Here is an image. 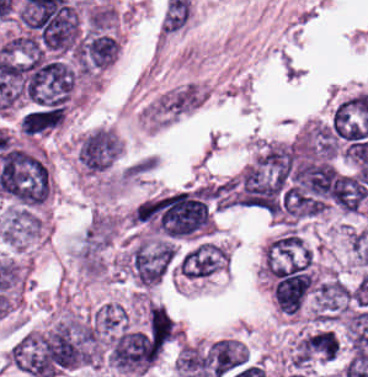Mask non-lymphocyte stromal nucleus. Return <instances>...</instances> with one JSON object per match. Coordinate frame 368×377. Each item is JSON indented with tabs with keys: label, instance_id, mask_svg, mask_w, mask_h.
Masks as SVG:
<instances>
[{
	"label": "non-lymphocyte stromal nucleus",
	"instance_id": "non-lymphocyte-stromal-nucleus-1",
	"mask_svg": "<svg viewBox=\"0 0 368 377\" xmlns=\"http://www.w3.org/2000/svg\"><path fill=\"white\" fill-rule=\"evenodd\" d=\"M121 140L110 128H97L84 136L78 158L92 171H104L117 157Z\"/></svg>",
	"mask_w": 368,
	"mask_h": 377
}]
</instances>
